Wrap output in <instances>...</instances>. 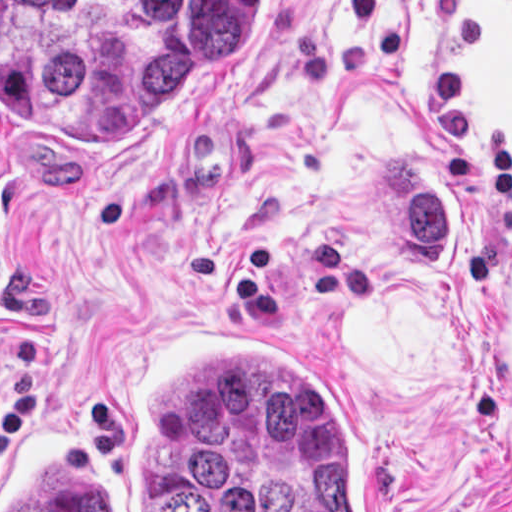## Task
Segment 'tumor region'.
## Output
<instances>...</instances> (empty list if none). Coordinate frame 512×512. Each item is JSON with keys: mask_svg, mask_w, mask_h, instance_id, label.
Listing matches in <instances>:
<instances>
[{"mask_svg": "<svg viewBox=\"0 0 512 512\" xmlns=\"http://www.w3.org/2000/svg\"><path fill=\"white\" fill-rule=\"evenodd\" d=\"M1 27L44 36L49 78L73 114L97 97L100 54L125 52V102L148 116L198 78L243 66L255 46V0H135L107 22L94 0H1ZM423 155L436 163L410 145L384 149L374 206L408 267L448 273L459 252L431 204Z\"/></svg>", "mask_w": 512, "mask_h": 512, "instance_id": "tumor-region-1", "label": "tumor region"}]
</instances>
